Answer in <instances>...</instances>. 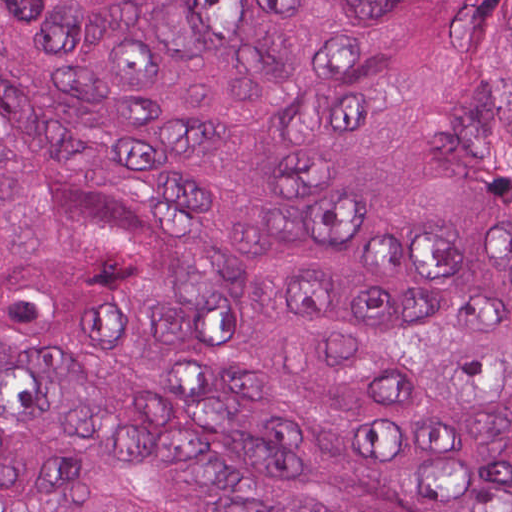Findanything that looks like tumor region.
Here are the masks:
<instances>
[{
  "instance_id": "e687c5a6",
  "label": "tumor region",
  "mask_w": 512,
  "mask_h": 512,
  "mask_svg": "<svg viewBox=\"0 0 512 512\" xmlns=\"http://www.w3.org/2000/svg\"><path fill=\"white\" fill-rule=\"evenodd\" d=\"M0 512H512V0H0Z\"/></svg>"
}]
</instances>
